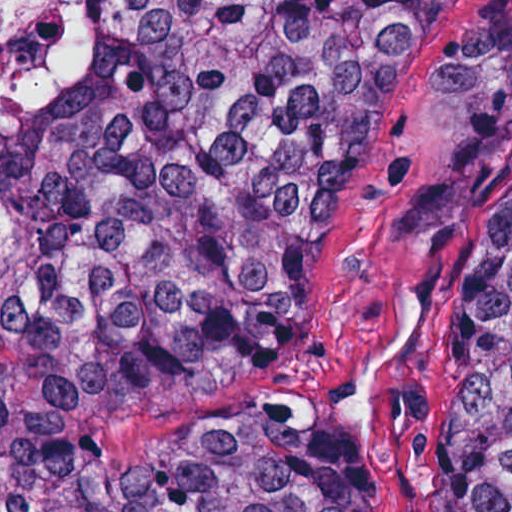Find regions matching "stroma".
<instances>
[{
	"label": "stroma",
	"instance_id": "35a3bbf8",
	"mask_svg": "<svg viewBox=\"0 0 512 512\" xmlns=\"http://www.w3.org/2000/svg\"><path fill=\"white\" fill-rule=\"evenodd\" d=\"M127 2L98 0L96 45ZM511 170L512 0H446L357 186L276 235L246 284L244 383L112 423L95 457L139 471L189 436L275 426L359 512H445L474 223Z\"/></svg>",
	"mask_w": 512,
	"mask_h": 512
}]
</instances>
